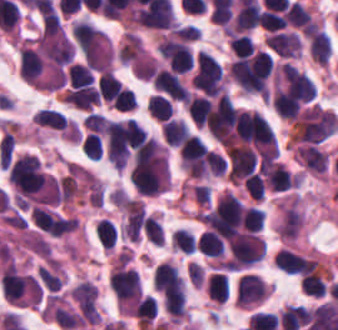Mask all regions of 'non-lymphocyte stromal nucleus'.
<instances>
[{
	"label": "non-lymphocyte stromal nucleus",
	"instance_id": "1",
	"mask_svg": "<svg viewBox=\"0 0 338 330\" xmlns=\"http://www.w3.org/2000/svg\"><path fill=\"white\" fill-rule=\"evenodd\" d=\"M303 223L298 196H290L278 205L277 235L293 241Z\"/></svg>",
	"mask_w": 338,
	"mask_h": 330
}]
</instances>
